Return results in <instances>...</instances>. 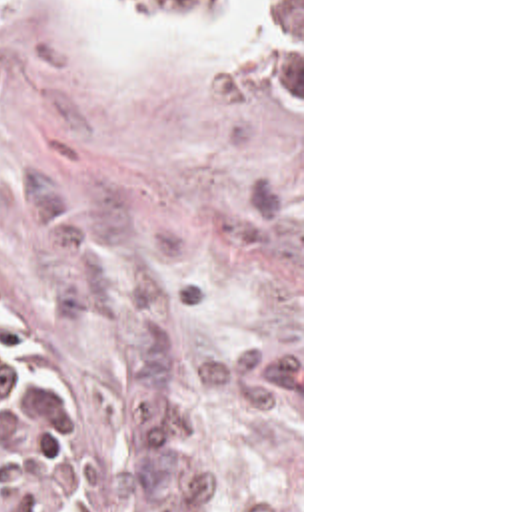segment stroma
<instances>
[{"instance_id":"35a3bbf8","label":"stroma","mask_w":512,"mask_h":512,"mask_svg":"<svg viewBox=\"0 0 512 512\" xmlns=\"http://www.w3.org/2000/svg\"><path fill=\"white\" fill-rule=\"evenodd\" d=\"M220 31L0 0V315L64 346L98 512H304L300 107Z\"/></svg>"}]
</instances>
